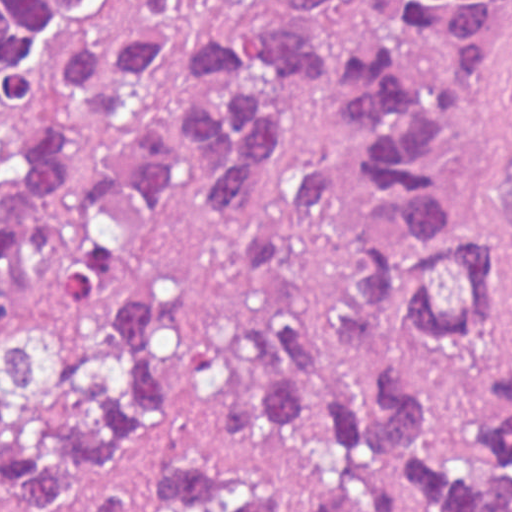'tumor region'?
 I'll use <instances>...</instances> for the list:
<instances>
[{
  "label": "tumor region",
  "instance_id": "tumor-region-1",
  "mask_svg": "<svg viewBox=\"0 0 512 512\" xmlns=\"http://www.w3.org/2000/svg\"><path fill=\"white\" fill-rule=\"evenodd\" d=\"M342 0H0V294L33 255L74 295L178 201L261 216L284 177L280 95L327 87L311 23ZM512 0H390L354 43L349 162H305L285 222L238 251L266 313L231 336L262 439L168 458L167 512H512V356L488 428L456 446L418 367L477 345L496 293L445 138L477 104ZM512 253V172L500 211ZM173 307L160 290L107 337L44 329L0 351V499L10 512L116 488L165 448Z\"/></svg>",
  "mask_w": 512,
  "mask_h": 512
}]
</instances>
